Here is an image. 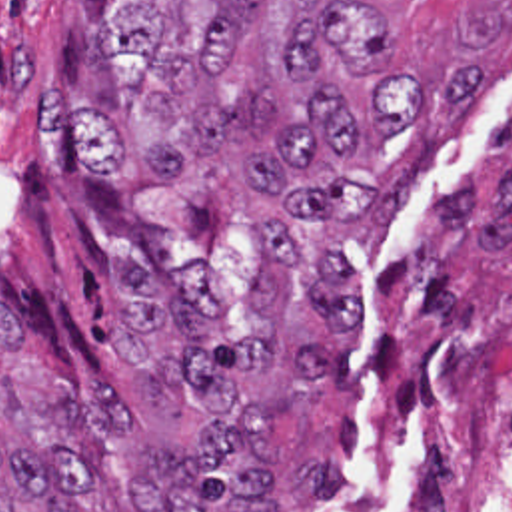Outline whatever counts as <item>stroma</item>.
Listing matches in <instances>:
<instances>
[{
    "mask_svg": "<svg viewBox=\"0 0 512 512\" xmlns=\"http://www.w3.org/2000/svg\"><path fill=\"white\" fill-rule=\"evenodd\" d=\"M355 1L385 11L423 73L469 51L479 75L455 129L405 175L379 241H343L367 279L359 314L321 396L267 418L281 512L395 510L373 476V434L423 354L453 338L512 342V0ZM131 5L0 0V308L45 364L119 382L149 440L197 444L203 414L181 384L119 370V271L203 269L231 328L263 332L253 251L271 209L209 161L173 179L85 173L67 129L45 127L49 89L75 109L119 107L95 39Z\"/></svg>",
    "mask_w": 512,
    "mask_h": 512,
    "instance_id": "stroma-1",
    "label": "stroma"
}]
</instances>
